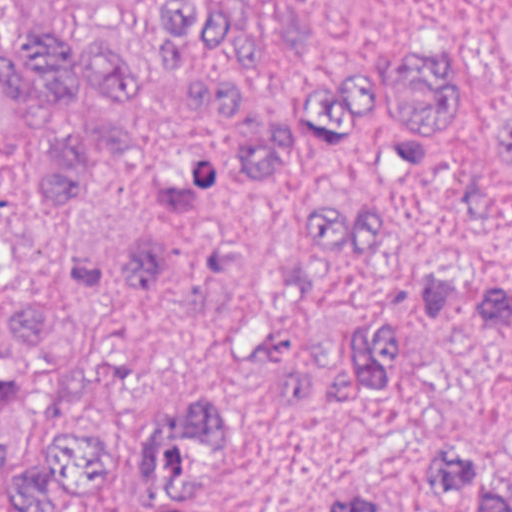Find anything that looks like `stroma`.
Wrapping results in <instances>:
<instances>
[{"instance_id":"35a3bbf8","label":"stroma","mask_w":512,"mask_h":512,"mask_svg":"<svg viewBox=\"0 0 512 512\" xmlns=\"http://www.w3.org/2000/svg\"><path fill=\"white\" fill-rule=\"evenodd\" d=\"M255 28L240 91L278 121L314 119L380 61L455 80L453 112L386 204L406 256L445 279L413 318L399 371L275 405L259 371L223 359L169 301L139 304L163 391L215 405L217 512H466L451 459L512 476V0H226Z\"/></svg>"}]
</instances>
